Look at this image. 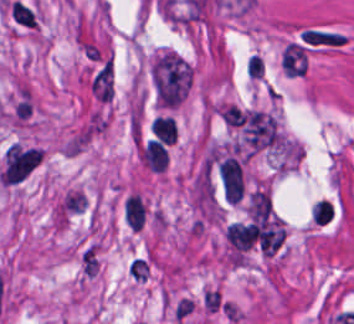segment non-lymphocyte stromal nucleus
Wrapping results in <instances>:
<instances>
[{"label":"non-lymphocyte stromal nucleus","mask_w":354,"mask_h":324,"mask_svg":"<svg viewBox=\"0 0 354 324\" xmlns=\"http://www.w3.org/2000/svg\"><path fill=\"white\" fill-rule=\"evenodd\" d=\"M244 130L249 144L258 147L271 143L277 135L275 118L255 109L247 113Z\"/></svg>","instance_id":"dd21d789"},{"label":"non-lymphocyte stromal nucleus","mask_w":354,"mask_h":324,"mask_svg":"<svg viewBox=\"0 0 354 324\" xmlns=\"http://www.w3.org/2000/svg\"><path fill=\"white\" fill-rule=\"evenodd\" d=\"M218 172L225 198L234 203L241 200L244 192L241 165L228 156L219 164Z\"/></svg>","instance_id":"a72fc3eb"},{"label":"non-lymphocyte stromal nucleus","mask_w":354,"mask_h":324,"mask_svg":"<svg viewBox=\"0 0 354 324\" xmlns=\"http://www.w3.org/2000/svg\"><path fill=\"white\" fill-rule=\"evenodd\" d=\"M271 202L262 190L254 191L249 197L248 216L256 222L270 221Z\"/></svg>","instance_id":"3746e769"},{"label":"non-lymphocyte stromal nucleus","mask_w":354,"mask_h":324,"mask_svg":"<svg viewBox=\"0 0 354 324\" xmlns=\"http://www.w3.org/2000/svg\"><path fill=\"white\" fill-rule=\"evenodd\" d=\"M92 91L102 99L112 96V62L107 58L91 79Z\"/></svg>","instance_id":"fc2b8d12"},{"label":"non-lymphocyte stromal nucleus","mask_w":354,"mask_h":324,"mask_svg":"<svg viewBox=\"0 0 354 324\" xmlns=\"http://www.w3.org/2000/svg\"><path fill=\"white\" fill-rule=\"evenodd\" d=\"M304 57L301 47L290 42L283 50L281 64L288 73H301Z\"/></svg>","instance_id":"81446118"}]
</instances>
